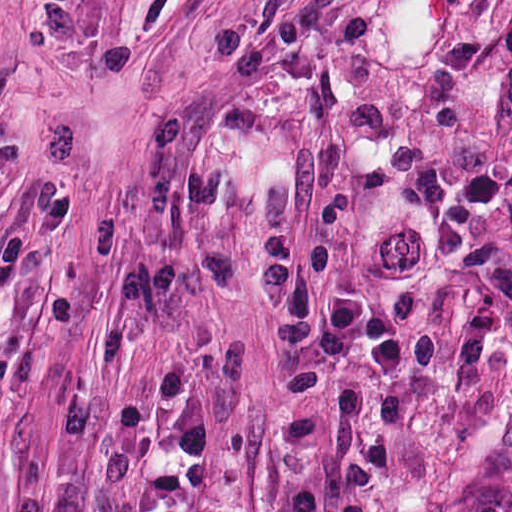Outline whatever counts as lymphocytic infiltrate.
<instances>
[{
    "label": "lymphocytic infiltrate",
    "instance_id": "obj_1",
    "mask_svg": "<svg viewBox=\"0 0 512 512\" xmlns=\"http://www.w3.org/2000/svg\"><path fill=\"white\" fill-rule=\"evenodd\" d=\"M62 190L33 202L0 238V309L10 300L23 264L64 221ZM294 236L283 233L266 248L255 283L254 313L264 336L279 391L296 407H312L333 390L339 363L360 350L380 378L406 376L408 343L389 310L375 300L329 285L332 250L311 249L301 270L290 268ZM344 418L368 413L373 426L342 460L326 494L295 487L285 512H370L389 485L397 442L407 422L395 386H365L340 397ZM171 422L175 448L188 468L213 460V434L200 378L188 361L169 356L122 403L117 436L141 493L144 512H200L190 482L169 468H146L141 434L152 419Z\"/></svg>",
    "mask_w": 512,
    "mask_h": 512
}]
</instances>
